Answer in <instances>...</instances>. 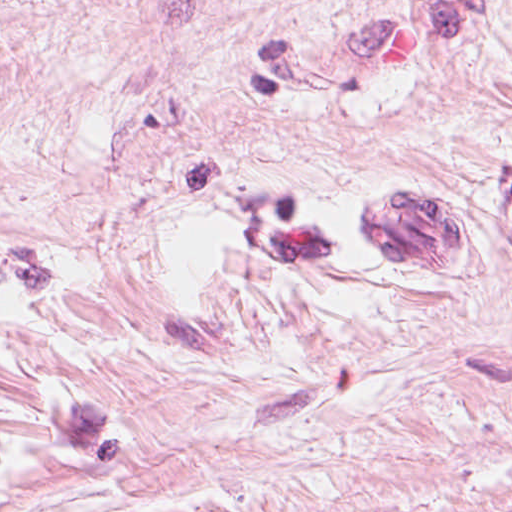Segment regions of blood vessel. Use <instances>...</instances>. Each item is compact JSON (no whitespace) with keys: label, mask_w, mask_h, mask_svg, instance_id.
<instances>
[{"label":"blood vessel","mask_w":512,"mask_h":512,"mask_svg":"<svg viewBox=\"0 0 512 512\" xmlns=\"http://www.w3.org/2000/svg\"><path fill=\"white\" fill-rule=\"evenodd\" d=\"M386 189L375 202V236L389 261H439L449 241L448 208Z\"/></svg>","instance_id":"8fb6f2fc"}]
</instances>
